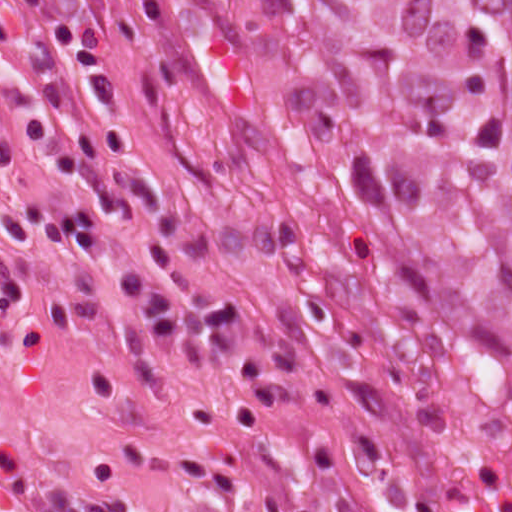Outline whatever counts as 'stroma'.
I'll use <instances>...</instances> for the list:
<instances>
[{
    "instance_id": "1",
    "label": "stroma",
    "mask_w": 512,
    "mask_h": 512,
    "mask_svg": "<svg viewBox=\"0 0 512 512\" xmlns=\"http://www.w3.org/2000/svg\"><path fill=\"white\" fill-rule=\"evenodd\" d=\"M0 122L18 152L0 216L71 210L120 163L169 195L98 210L90 262L15 253L32 297L0 314V512H512L511 443L355 367L312 229L170 0H0ZM125 268L245 300L241 346L155 351Z\"/></svg>"
}]
</instances>
